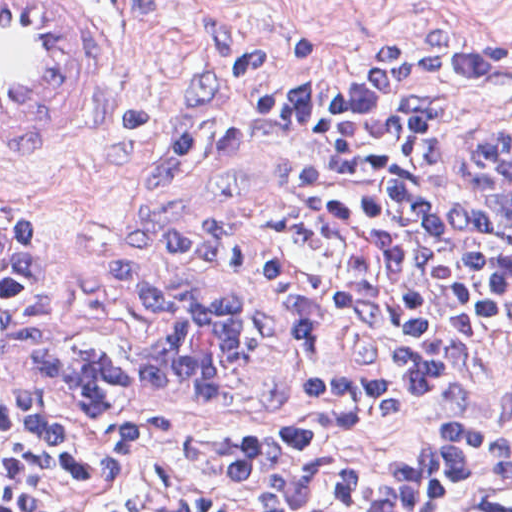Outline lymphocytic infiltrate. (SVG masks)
<instances>
[{
    "mask_svg": "<svg viewBox=\"0 0 512 512\" xmlns=\"http://www.w3.org/2000/svg\"><path fill=\"white\" fill-rule=\"evenodd\" d=\"M270 106L347 121L340 214L389 310L386 391L323 432L230 443L174 430L130 396L69 387L44 343L114 311L81 253L0 227V512H435L450 488L512 475V270L462 248L428 196L431 133L512 127V55L437 43L281 71ZM431 401L421 446L343 461L326 433L384 429Z\"/></svg>",
    "mask_w": 512,
    "mask_h": 512,
    "instance_id": "obj_1",
    "label": "lymphocytic infiltrate"
}]
</instances>
